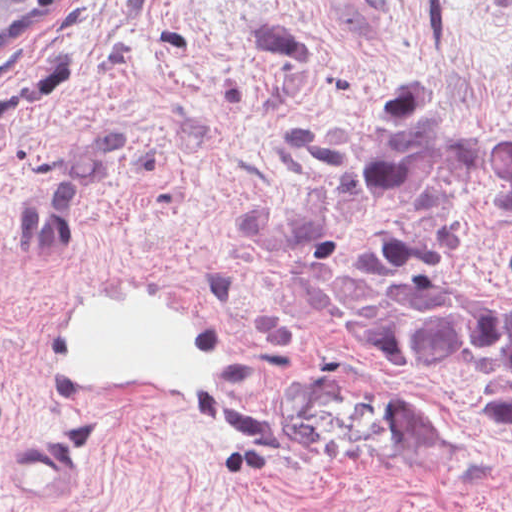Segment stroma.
<instances>
[{
  "label": "stroma",
  "mask_w": 512,
  "mask_h": 512,
  "mask_svg": "<svg viewBox=\"0 0 512 512\" xmlns=\"http://www.w3.org/2000/svg\"><path fill=\"white\" fill-rule=\"evenodd\" d=\"M394 73L427 76L471 131L512 134V0H82L0 67V512H512L491 396L340 346L248 246L255 191ZM449 261L458 284L512 294V214L458 200ZM81 275L197 292L279 447L68 415L46 322ZM41 431L72 455L55 500L6 476L8 446Z\"/></svg>",
  "instance_id": "stroma-1"
}]
</instances>
